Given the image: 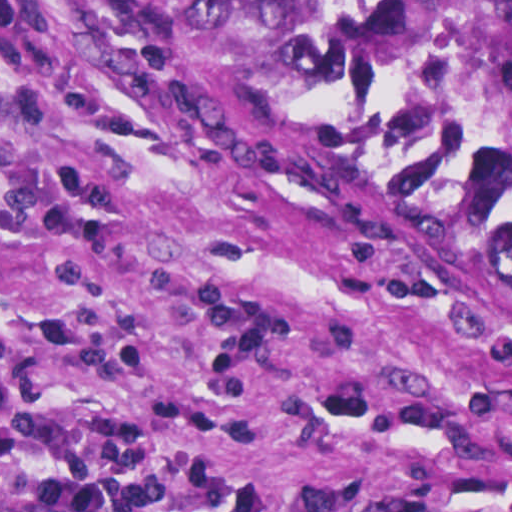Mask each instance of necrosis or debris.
Listing matches in <instances>:
<instances>
[{
    "label": "necrosis or debris",
    "instance_id": "1",
    "mask_svg": "<svg viewBox=\"0 0 512 512\" xmlns=\"http://www.w3.org/2000/svg\"><path fill=\"white\" fill-rule=\"evenodd\" d=\"M461 102L473 130L512 169V82L469 77Z\"/></svg>",
    "mask_w": 512,
    "mask_h": 512
}]
</instances>
